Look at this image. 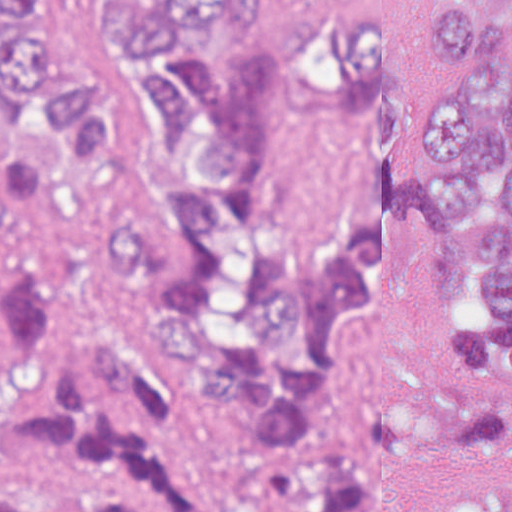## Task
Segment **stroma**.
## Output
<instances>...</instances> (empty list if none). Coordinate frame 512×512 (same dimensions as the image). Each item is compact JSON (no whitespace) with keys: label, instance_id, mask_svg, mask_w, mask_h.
Instances as JSON below:
<instances>
[{"label":"stroma","instance_id":"stroma-1","mask_svg":"<svg viewBox=\"0 0 512 512\" xmlns=\"http://www.w3.org/2000/svg\"><path fill=\"white\" fill-rule=\"evenodd\" d=\"M437 0H381L391 35L399 95L413 123L435 91V68L423 53L426 11ZM46 238L62 278L86 317L154 380L194 428L216 467L255 479L276 452L330 446L352 434L387 401L447 402L439 339L472 320L459 289L454 240L428 210L406 218L394 237L388 311L348 334L339 354V404L307 444H280L221 428L208 409L200 370L180 363L157 327L146 291L105 275L101 234L140 222V202L94 198L36 206L0 182ZM512 489V446H464L443 452L410 475L382 512H454L462 500Z\"/></svg>","mask_w":512,"mask_h":512}]
</instances>
